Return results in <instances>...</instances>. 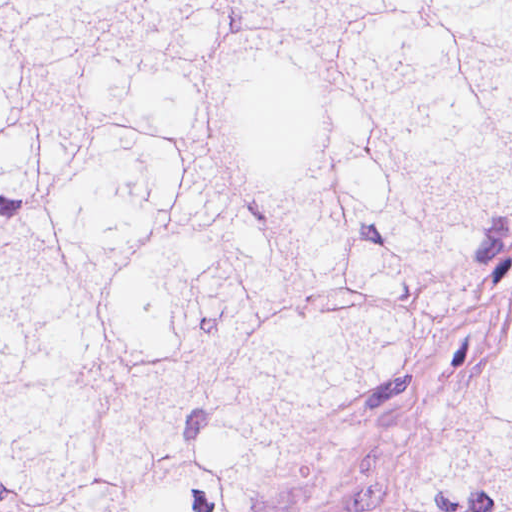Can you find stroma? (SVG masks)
<instances>
[{
	"instance_id": "35a3bbf8",
	"label": "stroma",
	"mask_w": 512,
	"mask_h": 512,
	"mask_svg": "<svg viewBox=\"0 0 512 512\" xmlns=\"http://www.w3.org/2000/svg\"><path fill=\"white\" fill-rule=\"evenodd\" d=\"M511 328L512 220L482 247L479 266L456 306L418 335L341 447L283 512H403L397 473L404 453L421 432L471 396Z\"/></svg>"
}]
</instances>
